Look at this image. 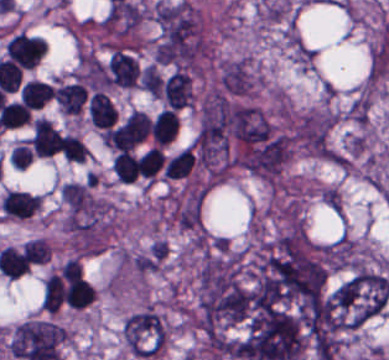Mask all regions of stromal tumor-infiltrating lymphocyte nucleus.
I'll return each mask as SVG.
<instances>
[{
    "label": "stromal tumor-infiltrating lymphocyte nucleus",
    "instance_id": "1",
    "mask_svg": "<svg viewBox=\"0 0 389 360\" xmlns=\"http://www.w3.org/2000/svg\"><path fill=\"white\" fill-rule=\"evenodd\" d=\"M148 134V115L133 109L108 130L109 146L114 150L129 151Z\"/></svg>",
    "mask_w": 389,
    "mask_h": 360
},
{
    "label": "stromal tumor-infiltrating lymphocyte nucleus",
    "instance_id": "2",
    "mask_svg": "<svg viewBox=\"0 0 389 360\" xmlns=\"http://www.w3.org/2000/svg\"><path fill=\"white\" fill-rule=\"evenodd\" d=\"M46 51V41L42 37L18 33L10 37L5 54L19 67L31 68Z\"/></svg>",
    "mask_w": 389,
    "mask_h": 360
},
{
    "label": "stromal tumor-infiltrating lymphocyte nucleus",
    "instance_id": "3",
    "mask_svg": "<svg viewBox=\"0 0 389 360\" xmlns=\"http://www.w3.org/2000/svg\"><path fill=\"white\" fill-rule=\"evenodd\" d=\"M164 104L179 108L192 99L191 78L182 70L174 69L161 83Z\"/></svg>",
    "mask_w": 389,
    "mask_h": 360
},
{
    "label": "stromal tumor-infiltrating lymphocyte nucleus",
    "instance_id": "4",
    "mask_svg": "<svg viewBox=\"0 0 389 360\" xmlns=\"http://www.w3.org/2000/svg\"><path fill=\"white\" fill-rule=\"evenodd\" d=\"M30 143L35 155L39 156H49L61 145L55 126L42 117L32 122Z\"/></svg>",
    "mask_w": 389,
    "mask_h": 360
},
{
    "label": "stromal tumor-infiltrating lymphocyte nucleus",
    "instance_id": "5",
    "mask_svg": "<svg viewBox=\"0 0 389 360\" xmlns=\"http://www.w3.org/2000/svg\"><path fill=\"white\" fill-rule=\"evenodd\" d=\"M0 204L6 216L28 218L41 205V196L23 191L8 190L2 197Z\"/></svg>",
    "mask_w": 389,
    "mask_h": 360
},
{
    "label": "stromal tumor-infiltrating lymphocyte nucleus",
    "instance_id": "6",
    "mask_svg": "<svg viewBox=\"0 0 389 360\" xmlns=\"http://www.w3.org/2000/svg\"><path fill=\"white\" fill-rule=\"evenodd\" d=\"M138 74V67L133 57L114 49L109 56L107 82L132 86Z\"/></svg>",
    "mask_w": 389,
    "mask_h": 360
},
{
    "label": "stromal tumor-infiltrating lymphocyte nucleus",
    "instance_id": "7",
    "mask_svg": "<svg viewBox=\"0 0 389 360\" xmlns=\"http://www.w3.org/2000/svg\"><path fill=\"white\" fill-rule=\"evenodd\" d=\"M86 91L83 84L67 83L52 91V99L65 114H80L86 98Z\"/></svg>",
    "mask_w": 389,
    "mask_h": 360
},
{
    "label": "stromal tumor-infiltrating lymphocyte nucleus",
    "instance_id": "8",
    "mask_svg": "<svg viewBox=\"0 0 389 360\" xmlns=\"http://www.w3.org/2000/svg\"><path fill=\"white\" fill-rule=\"evenodd\" d=\"M115 116L114 105L102 91H94L88 100V118L91 124L101 128L113 125Z\"/></svg>",
    "mask_w": 389,
    "mask_h": 360
},
{
    "label": "stromal tumor-infiltrating lymphocyte nucleus",
    "instance_id": "9",
    "mask_svg": "<svg viewBox=\"0 0 389 360\" xmlns=\"http://www.w3.org/2000/svg\"><path fill=\"white\" fill-rule=\"evenodd\" d=\"M177 115L170 108L158 111L150 123V135L155 145H164L176 134Z\"/></svg>",
    "mask_w": 389,
    "mask_h": 360
},
{
    "label": "stromal tumor-infiltrating lymphocyte nucleus",
    "instance_id": "10",
    "mask_svg": "<svg viewBox=\"0 0 389 360\" xmlns=\"http://www.w3.org/2000/svg\"><path fill=\"white\" fill-rule=\"evenodd\" d=\"M52 93L49 83L37 78H30L19 91V96L27 108H41Z\"/></svg>",
    "mask_w": 389,
    "mask_h": 360
},
{
    "label": "stromal tumor-infiltrating lymphocyte nucleus",
    "instance_id": "11",
    "mask_svg": "<svg viewBox=\"0 0 389 360\" xmlns=\"http://www.w3.org/2000/svg\"><path fill=\"white\" fill-rule=\"evenodd\" d=\"M94 295L89 283L76 275L67 283L63 293L67 305L82 309L92 301Z\"/></svg>",
    "mask_w": 389,
    "mask_h": 360
},
{
    "label": "stromal tumor-infiltrating lymphocyte nucleus",
    "instance_id": "12",
    "mask_svg": "<svg viewBox=\"0 0 389 360\" xmlns=\"http://www.w3.org/2000/svg\"><path fill=\"white\" fill-rule=\"evenodd\" d=\"M64 286L61 275L50 273L42 282L41 305L47 312H54L63 301Z\"/></svg>",
    "mask_w": 389,
    "mask_h": 360
},
{
    "label": "stromal tumor-infiltrating lymphocyte nucleus",
    "instance_id": "13",
    "mask_svg": "<svg viewBox=\"0 0 389 360\" xmlns=\"http://www.w3.org/2000/svg\"><path fill=\"white\" fill-rule=\"evenodd\" d=\"M195 158L187 145L168 159L164 167V176L170 178L185 177L191 170Z\"/></svg>",
    "mask_w": 389,
    "mask_h": 360
},
{
    "label": "stromal tumor-infiltrating lymphocyte nucleus",
    "instance_id": "14",
    "mask_svg": "<svg viewBox=\"0 0 389 360\" xmlns=\"http://www.w3.org/2000/svg\"><path fill=\"white\" fill-rule=\"evenodd\" d=\"M110 167L119 181L133 182L138 175V166L132 154L121 151L110 161Z\"/></svg>",
    "mask_w": 389,
    "mask_h": 360
},
{
    "label": "stromal tumor-infiltrating lymphocyte nucleus",
    "instance_id": "15",
    "mask_svg": "<svg viewBox=\"0 0 389 360\" xmlns=\"http://www.w3.org/2000/svg\"><path fill=\"white\" fill-rule=\"evenodd\" d=\"M164 162V155L157 146H150L138 161V175L154 177Z\"/></svg>",
    "mask_w": 389,
    "mask_h": 360
},
{
    "label": "stromal tumor-infiltrating lymphocyte nucleus",
    "instance_id": "16",
    "mask_svg": "<svg viewBox=\"0 0 389 360\" xmlns=\"http://www.w3.org/2000/svg\"><path fill=\"white\" fill-rule=\"evenodd\" d=\"M61 152L65 160L84 161L89 155L88 148L74 135H61Z\"/></svg>",
    "mask_w": 389,
    "mask_h": 360
},
{
    "label": "stromal tumor-infiltrating lymphocyte nucleus",
    "instance_id": "17",
    "mask_svg": "<svg viewBox=\"0 0 389 360\" xmlns=\"http://www.w3.org/2000/svg\"><path fill=\"white\" fill-rule=\"evenodd\" d=\"M50 249V245L43 237L27 239L24 243V253L30 263H45Z\"/></svg>",
    "mask_w": 389,
    "mask_h": 360
}]
</instances>
